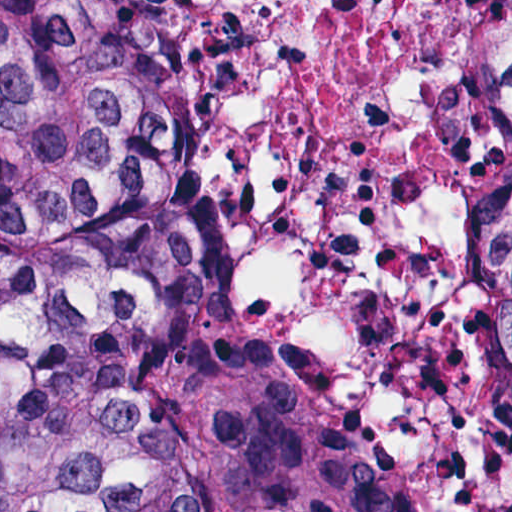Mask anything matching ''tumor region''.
<instances>
[{
  "label": "tumor region",
  "instance_id": "obj_1",
  "mask_svg": "<svg viewBox=\"0 0 512 512\" xmlns=\"http://www.w3.org/2000/svg\"><path fill=\"white\" fill-rule=\"evenodd\" d=\"M0 512H380L282 340L208 305V121L153 0H0Z\"/></svg>",
  "mask_w": 512,
  "mask_h": 512
}]
</instances>
